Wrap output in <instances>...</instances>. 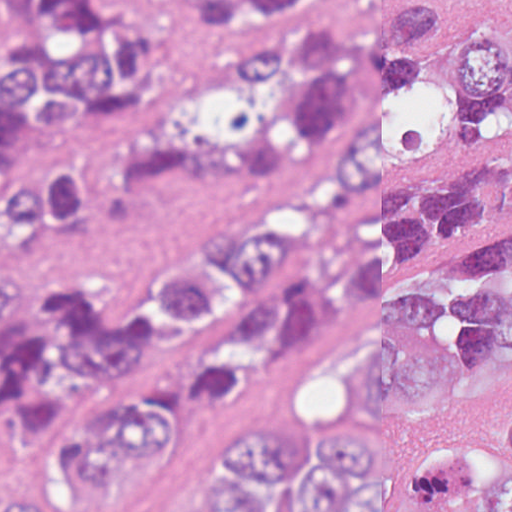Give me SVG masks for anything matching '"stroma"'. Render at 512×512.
Segmentation results:
<instances>
[{
	"mask_svg": "<svg viewBox=\"0 0 512 512\" xmlns=\"http://www.w3.org/2000/svg\"><path fill=\"white\" fill-rule=\"evenodd\" d=\"M501 162H512V99L479 108L453 137L363 189L350 219L389 193L444 170ZM340 183L286 216L297 220L315 217L338 193ZM510 221L512 217L473 221L450 241L400 257L397 263L430 262L453 252L477 233ZM190 265L133 270L81 287L96 291L116 312L136 317L170 280L186 276ZM310 265L299 252L276 260L245 297L229 305L211 334L130 374L109 375L98 383L66 429L54 437L13 443L8 411L2 412L0 512H8L14 496L47 499L78 485L43 505V512H203L209 498V455L217 435L233 420L328 423L367 443L383 460L400 464L439 439L486 438L510 387L512 362L455 391L434 408L414 412L378 408L355 385V356L372 335L367 309L345 315L324 341L280 367L270 384L251 394L220 402H197L183 396L184 374L225 318L262 294L302 280ZM44 296L28 295L30 301ZM108 397L157 403L160 440L154 452H127L133 457L128 462L81 485L90 479L86 467L57 452L59 439L98 414Z\"/></svg>",
	"mask_w": 512,
	"mask_h": 512,
	"instance_id": "35a3bbf8",
	"label": "stroma"
}]
</instances>
